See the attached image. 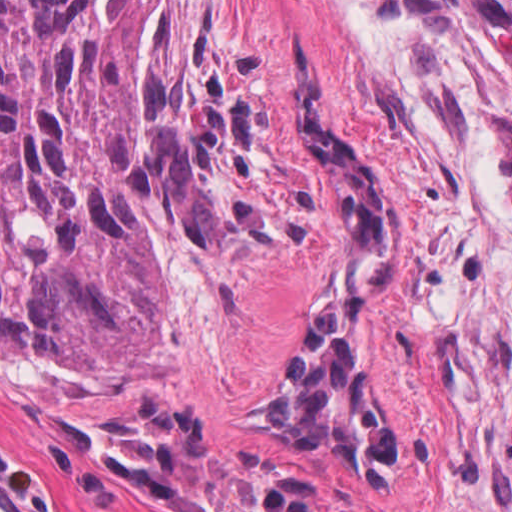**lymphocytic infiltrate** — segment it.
<instances>
[{
	"label": "lymphocytic infiltrate",
	"mask_w": 512,
	"mask_h": 512,
	"mask_svg": "<svg viewBox=\"0 0 512 512\" xmlns=\"http://www.w3.org/2000/svg\"><path fill=\"white\" fill-rule=\"evenodd\" d=\"M353 23L377 37L428 44L463 56L489 87L512 104V0H343ZM0 482L32 509L48 496L0 433Z\"/></svg>",
	"instance_id": "lymphocytic-infiltrate-1"
}]
</instances>
